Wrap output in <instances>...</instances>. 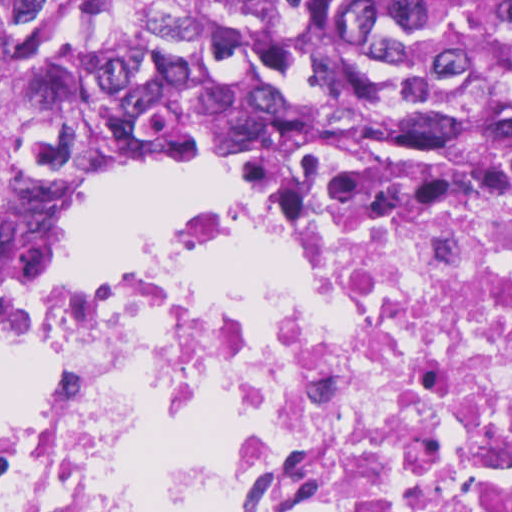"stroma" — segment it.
<instances>
[{"mask_svg": "<svg viewBox=\"0 0 512 512\" xmlns=\"http://www.w3.org/2000/svg\"><path fill=\"white\" fill-rule=\"evenodd\" d=\"M253 161L256 160H170L112 169L92 177L79 188H77L65 203V205H67L82 193L102 190L133 182L154 172L179 164L228 168L240 176L238 167ZM246 199H248V197L245 193L244 180L243 201ZM56 214L57 212H55L45 221L24 232L16 252L12 275L0 286V301L16 285L31 275L42 249L53 233ZM163 226L164 224H151L138 235H136L124 253L123 257L101 278L113 275L131 263L146 256ZM36 328L37 325L18 340L12 359L0 382V401L8 390L9 386L23 373L26 365L32 357Z\"/></svg>", "mask_w": 512, "mask_h": 512, "instance_id": "35a3bbf8", "label": "stroma"}]
</instances>
